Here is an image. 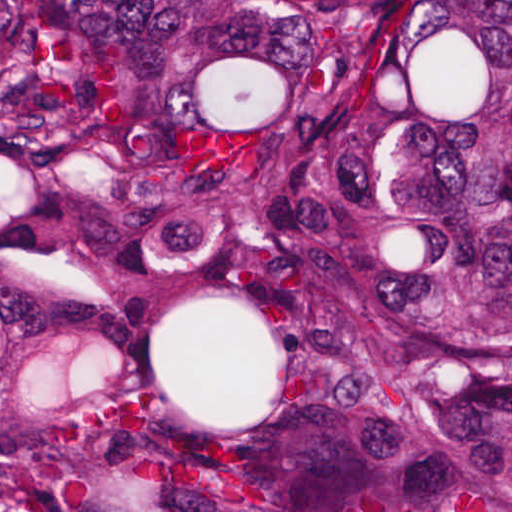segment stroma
Returning <instances> with one entry per match:
<instances>
[{
  "instance_id": "35a3bbf8",
  "label": "stroma",
  "mask_w": 512,
  "mask_h": 512,
  "mask_svg": "<svg viewBox=\"0 0 512 512\" xmlns=\"http://www.w3.org/2000/svg\"><path fill=\"white\" fill-rule=\"evenodd\" d=\"M5 1H512V0H0V512L6 505L42 512L25 489L13 461L4 412V203L8 156L4 134V2Z\"/></svg>"
}]
</instances>
